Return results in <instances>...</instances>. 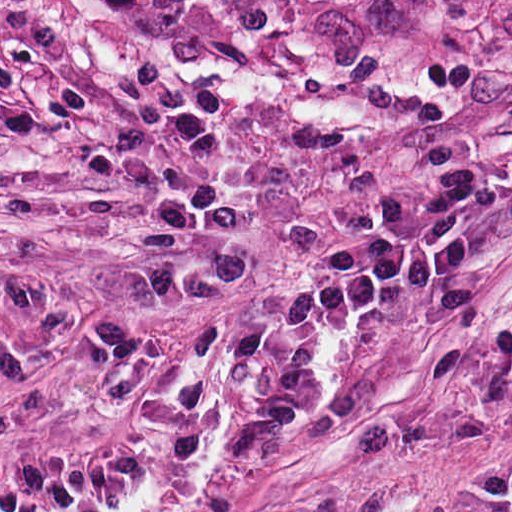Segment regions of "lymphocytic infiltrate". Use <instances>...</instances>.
<instances>
[{"label": "lymphocytic infiltrate", "mask_w": 512, "mask_h": 512, "mask_svg": "<svg viewBox=\"0 0 512 512\" xmlns=\"http://www.w3.org/2000/svg\"><path fill=\"white\" fill-rule=\"evenodd\" d=\"M441 188L422 204L423 227L413 224L408 203H384L376 231L340 240L317 262L310 284L289 298L254 310L230 333L225 361L248 368L283 347L273 378L243 421L228 434L227 453L254 458L302 412L316 384L311 352L317 330L329 323L376 316L412 284L458 266L474 251L469 221L482 184L512 181V161L488 164L446 146L427 159Z\"/></svg>", "instance_id": "obj_1"}]
</instances>
